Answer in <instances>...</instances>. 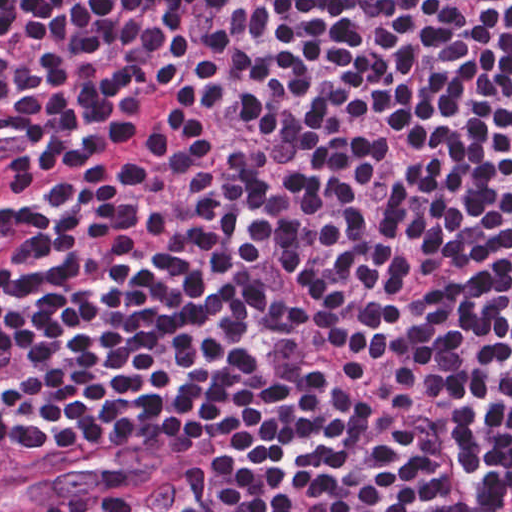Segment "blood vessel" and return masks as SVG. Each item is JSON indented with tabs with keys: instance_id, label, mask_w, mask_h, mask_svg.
Listing matches in <instances>:
<instances>
[{
	"instance_id": "8fb6f2fc",
	"label": "blood vessel",
	"mask_w": 512,
	"mask_h": 512,
	"mask_svg": "<svg viewBox=\"0 0 512 512\" xmlns=\"http://www.w3.org/2000/svg\"><path fill=\"white\" fill-rule=\"evenodd\" d=\"M166 459L163 443L151 440L128 441L80 454L31 479L0 484V512H32L103 476L151 468Z\"/></svg>"
}]
</instances>
